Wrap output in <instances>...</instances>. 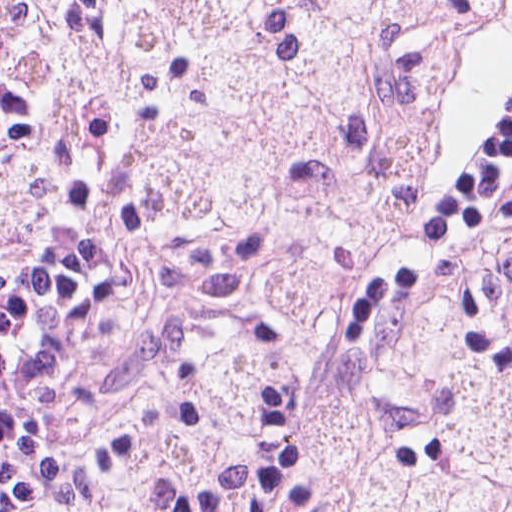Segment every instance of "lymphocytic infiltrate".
I'll list each match as a JSON object with an SVG mask.
<instances>
[{"label": "lymphocytic infiltrate", "mask_w": 512, "mask_h": 512, "mask_svg": "<svg viewBox=\"0 0 512 512\" xmlns=\"http://www.w3.org/2000/svg\"><path fill=\"white\" fill-rule=\"evenodd\" d=\"M128 251L37 111L25 1H0V512H63L33 469L39 435Z\"/></svg>", "instance_id": "f902f5d3"}]
</instances>
